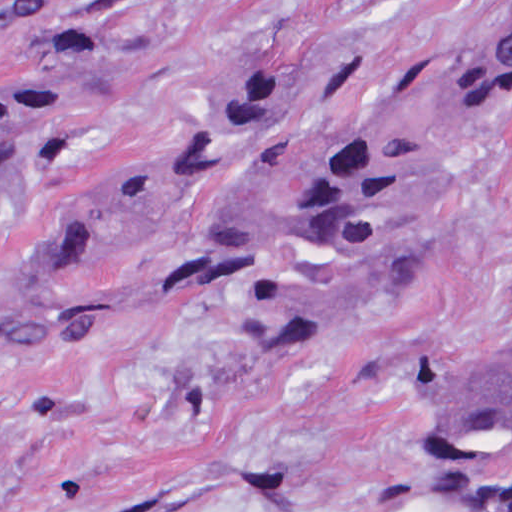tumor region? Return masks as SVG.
<instances>
[{"label": "tumor region", "mask_w": 512, "mask_h": 512, "mask_svg": "<svg viewBox=\"0 0 512 512\" xmlns=\"http://www.w3.org/2000/svg\"><path fill=\"white\" fill-rule=\"evenodd\" d=\"M85 0H0L19 34L68 28ZM116 65L66 66L0 97V210L60 159ZM289 66L240 71L202 92L131 173L82 203L36 263L0 282V338H286L343 353L415 264L428 201L401 147L350 136L298 197L255 209L251 175L298 114ZM512 117V0L501 15L481 136ZM430 416L426 466L459 484L512 461V340L415 362Z\"/></svg>", "instance_id": "e687c5a6"}]
</instances>
